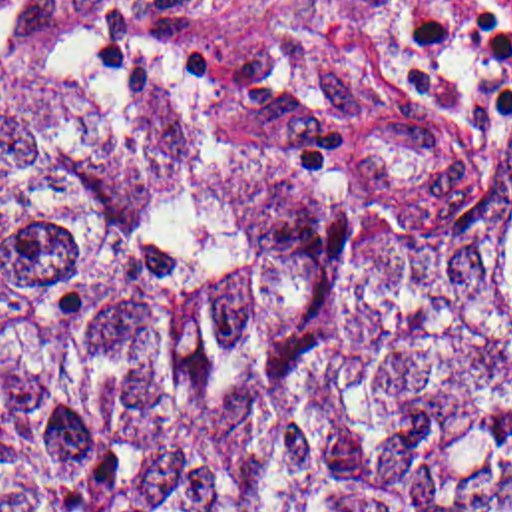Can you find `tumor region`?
<instances>
[{"instance_id":"tumor-region-1","label":"tumor region","mask_w":512,"mask_h":512,"mask_svg":"<svg viewBox=\"0 0 512 512\" xmlns=\"http://www.w3.org/2000/svg\"><path fill=\"white\" fill-rule=\"evenodd\" d=\"M236 1L0 0V512H512V117L376 157Z\"/></svg>"}]
</instances>
